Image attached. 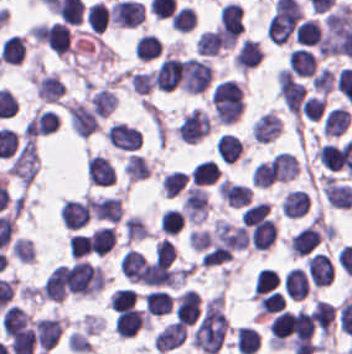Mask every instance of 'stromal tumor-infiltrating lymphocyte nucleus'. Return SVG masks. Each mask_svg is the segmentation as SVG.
<instances>
[{"mask_svg":"<svg viewBox=\"0 0 352 354\" xmlns=\"http://www.w3.org/2000/svg\"><path fill=\"white\" fill-rule=\"evenodd\" d=\"M222 43L218 27L205 30L196 39L195 50L202 55H216Z\"/></svg>","mask_w":352,"mask_h":354,"instance_id":"40","label":"stromal tumor-infiltrating lymphocyte nucleus"},{"mask_svg":"<svg viewBox=\"0 0 352 354\" xmlns=\"http://www.w3.org/2000/svg\"><path fill=\"white\" fill-rule=\"evenodd\" d=\"M186 182L185 171L171 170L160 181L161 192L165 197H172Z\"/></svg>","mask_w":352,"mask_h":354,"instance_id":"49","label":"stromal tumor-infiltrating lymphocyte nucleus"},{"mask_svg":"<svg viewBox=\"0 0 352 354\" xmlns=\"http://www.w3.org/2000/svg\"><path fill=\"white\" fill-rule=\"evenodd\" d=\"M309 206V197L304 190L292 189L281 200L280 212L287 217H300Z\"/></svg>","mask_w":352,"mask_h":354,"instance_id":"29","label":"stromal tumor-infiltrating lymphocyte nucleus"},{"mask_svg":"<svg viewBox=\"0 0 352 354\" xmlns=\"http://www.w3.org/2000/svg\"><path fill=\"white\" fill-rule=\"evenodd\" d=\"M185 217L181 209L168 208L163 212L160 230L166 235H175L182 227Z\"/></svg>","mask_w":352,"mask_h":354,"instance_id":"48","label":"stromal tumor-infiltrating lymphocyte nucleus"},{"mask_svg":"<svg viewBox=\"0 0 352 354\" xmlns=\"http://www.w3.org/2000/svg\"><path fill=\"white\" fill-rule=\"evenodd\" d=\"M260 346V337L249 325H242L235 330L236 350L243 354H251Z\"/></svg>","mask_w":352,"mask_h":354,"instance_id":"36","label":"stromal tumor-infiltrating lymphocyte nucleus"},{"mask_svg":"<svg viewBox=\"0 0 352 354\" xmlns=\"http://www.w3.org/2000/svg\"><path fill=\"white\" fill-rule=\"evenodd\" d=\"M311 86L316 91L328 92L334 85V74L326 68L319 69L310 79Z\"/></svg>","mask_w":352,"mask_h":354,"instance_id":"57","label":"stromal tumor-infiltrating lymphocyte nucleus"},{"mask_svg":"<svg viewBox=\"0 0 352 354\" xmlns=\"http://www.w3.org/2000/svg\"><path fill=\"white\" fill-rule=\"evenodd\" d=\"M220 29L227 37H235L241 31L242 7L233 1H226L218 10Z\"/></svg>","mask_w":352,"mask_h":354,"instance_id":"20","label":"stromal tumor-infiltrating lymphocyte nucleus"},{"mask_svg":"<svg viewBox=\"0 0 352 354\" xmlns=\"http://www.w3.org/2000/svg\"><path fill=\"white\" fill-rule=\"evenodd\" d=\"M128 82L134 93L148 94L151 87V76L145 70H129Z\"/></svg>","mask_w":352,"mask_h":354,"instance_id":"55","label":"stromal tumor-infiltrating lymphocyte nucleus"},{"mask_svg":"<svg viewBox=\"0 0 352 354\" xmlns=\"http://www.w3.org/2000/svg\"><path fill=\"white\" fill-rule=\"evenodd\" d=\"M119 261L125 279L139 281L146 263L140 250L127 248L121 255Z\"/></svg>","mask_w":352,"mask_h":354,"instance_id":"32","label":"stromal tumor-infiltrating lymphocyte nucleus"},{"mask_svg":"<svg viewBox=\"0 0 352 354\" xmlns=\"http://www.w3.org/2000/svg\"><path fill=\"white\" fill-rule=\"evenodd\" d=\"M27 313L14 305L4 308L0 319V328L2 330L26 326L30 322Z\"/></svg>","mask_w":352,"mask_h":354,"instance_id":"47","label":"stromal tumor-infiltrating lymphocyte nucleus"},{"mask_svg":"<svg viewBox=\"0 0 352 354\" xmlns=\"http://www.w3.org/2000/svg\"><path fill=\"white\" fill-rule=\"evenodd\" d=\"M78 264L55 266L41 286V297L61 301L77 280Z\"/></svg>","mask_w":352,"mask_h":354,"instance_id":"4","label":"stromal tumor-infiltrating lymphocyte nucleus"},{"mask_svg":"<svg viewBox=\"0 0 352 354\" xmlns=\"http://www.w3.org/2000/svg\"><path fill=\"white\" fill-rule=\"evenodd\" d=\"M64 89L63 83L53 74L41 75L35 81V95L46 101L59 99Z\"/></svg>","mask_w":352,"mask_h":354,"instance_id":"34","label":"stromal tumor-infiltrating lymphocyte nucleus"},{"mask_svg":"<svg viewBox=\"0 0 352 354\" xmlns=\"http://www.w3.org/2000/svg\"><path fill=\"white\" fill-rule=\"evenodd\" d=\"M277 234L273 218H266L250 229L247 234L248 243L252 248L267 249Z\"/></svg>","mask_w":352,"mask_h":354,"instance_id":"25","label":"stromal tumor-infiltrating lymphocyte nucleus"},{"mask_svg":"<svg viewBox=\"0 0 352 354\" xmlns=\"http://www.w3.org/2000/svg\"><path fill=\"white\" fill-rule=\"evenodd\" d=\"M38 166V153L35 140L25 137L9 165L10 172L24 185H28Z\"/></svg>","mask_w":352,"mask_h":354,"instance_id":"5","label":"stromal tumor-infiltrating lymphocyte nucleus"},{"mask_svg":"<svg viewBox=\"0 0 352 354\" xmlns=\"http://www.w3.org/2000/svg\"><path fill=\"white\" fill-rule=\"evenodd\" d=\"M210 126L206 111L194 106L182 116L175 131L183 141L195 142L210 129Z\"/></svg>","mask_w":352,"mask_h":354,"instance_id":"8","label":"stromal tumor-infiltrating lymphocyte nucleus"},{"mask_svg":"<svg viewBox=\"0 0 352 354\" xmlns=\"http://www.w3.org/2000/svg\"><path fill=\"white\" fill-rule=\"evenodd\" d=\"M170 22L176 31H190L196 22L195 8L186 4L175 8Z\"/></svg>","mask_w":352,"mask_h":354,"instance_id":"44","label":"stromal tumor-infiltrating lymphocyte nucleus"},{"mask_svg":"<svg viewBox=\"0 0 352 354\" xmlns=\"http://www.w3.org/2000/svg\"><path fill=\"white\" fill-rule=\"evenodd\" d=\"M63 226L79 229L89 221V206L84 199L66 198L60 208Z\"/></svg>","mask_w":352,"mask_h":354,"instance_id":"13","label":"stromal tumor-infiltrating lymphocyte nucleus"},{"mask_svg":"<svg viewBox=\"0 0 352 354\" xmlns=\"http://www.w3.org/2000/svg\"><path fill=\"white\" fill-rule=\"evenodd\" d=\"M281 119L272 110H264L253 119L252 136L254 141H267L278 135Z\"/></svg>","mask_w":352,"mask_h":354,"instance_id":"19","label":"stromal tumor-infiltrating lymphocyte nucleus"},{"mask_svg":"<svg viewBox=\"0 0 352 354\" xmlns=\"http://www.w3.org/2000/svg\"><path fill=\"white\" fill-rule=\"evenodd\" d=\"M320 164L329 171H337L340 168V145L323 142L316 147Z\"/></svg>","mask_w":352,"mask_h":354,"instance_id":"46","label":"stromal tumor-infiltrating lymphocyte nucleus"},{"mask_svg":"<svg viewBox=\"0 0 352 354\" xmlns=\"http://www.w3.org/2000/svg\"><path fill=\"white\" fill-rule=\"evenodd\" d=\"M145 307L152 315H162L167 313L172 301L165 290L153 289L143 296Z\"/></svg>","mask_w":352,"mask_h":354,"instance_id":"39","label":"stromal tumor-infiltrating lymphocyte nucleus"},{"mask_svg":"<svg viewBox=\"0 0 352 354\" xmlns=\"http://www.w3.org/2000/svg\"><path fill=\"white\" fill-rule=\"evenodd\" d=\"M160 50L161 43L151 32L139 36L134 46L135 55L147 60L156 57Z\"/></svg>","mask_w":352,"mask_h":354,"instance_id":"43","label":"stromal tumor-infiltrating lymphocyte nucleus"},{"mask_svg":"<svg viewBox=\"0 0 352 354\" xmlns=\"http://www.w3.org/2000/svg\"><path fill=\"white\" fill-rule=\"evenodd\" d=\"M282 288L287 295L295 300L307 294L309 283L299 266H292L283 274Z\"/></svg>","mask_w":352,"mask_h":354,"instance_id":"27","label":"stromal tumor-infiltrating lymphocyte nucleus"},{"mask_svg":"<svg viewBox=\"0 0 352 354\" xmlns=\"http://www.w3.org/2000/svg\"><path fill=\"white\" fill-rule=\"evenodd\" d=\"M279 280L273 269L261 268L254 274L252 284V297H260L272 291Z\"/></svg>","mask_w":352,"mask_h":354,"instance_id":"41","label":"stromal tumor-infiltrating lymphocyte nucleus"},{"mask_svg":"<svg viewBox=\"0 0 352 354\" xmlns=\"http://www.w3.org/2000/svg\"><path fill=\"white\" fill-rule=\"evenodd\" d=\"M85 22L94 31H103L107 26V7L102 1H95L85 10Z\"/></svg>","mask_w":352,"mask_h":354,"instance_id":"45","label":"stromal tumor-infiltrating lymphocyte nucleus"},{"mask_svg":"<svg viewBox=\"0 0 352 354\" xmlns=\"http://www.w3.org/2000/svg\"><path fill=\"white\" fill-rule=\"evenodd\" d=\"M285 302L280 292L270 291L258 297L257 308L259 315L279 312Z\"/></svg>","mask_w":352,"mask_h":354,"instance_id":"52","label":"stromal tumor-infiltrating lymphocyte nucleus"},{"mask_svg":"<svg viewBox=\"0 0 352 354\" xmlns=\"http://www.w3.org/2000/svg\"><path fill=\"white\" fill-rule=\"evenodd\" d=\"M263 56L257 41L252 38H245L235 53L236 64L238 67H252Z\"/></svg>","mask_w":352,"mask_h":354,"instance_id":"35","label":"stromal tumor-infiltrating lymphocyte nucleus"},{"mask_svg":"<svg viewBox=\"0 0 352 354\" xmlns=\"http://www.w3.org/2000/svg\"><path fill=\"white\" fill-rule=\"evenodd\" d=\"M144 327L143 310L129 306L121 309L113 320L114 332L121 337H131Z\"/></svg>","mask_w":352,"mask_h":354,"instance_id":"15","label":"stromal tumor-infiltrating lymphocyte nucleus"},{"mask_svg":"<svg viewBox=\"0 0 352 354\" xmlns=\"http://www.w3.org/2000/svg\"><path fill=\"white\" fill-rule=\"evenodd\" d=\"M298 20L293 16L272 13L267 20L266 33L272 42H285L291 34Z\"/></svg>","mask_w":352,"mask_h":354,"instance_id":"24","label":"stromal tumor-infiltrating lymphocyte nucleus"},{"mask_svg":"<svg viewBox=\"0 0 352 354\" xmlns=\"http://www.w3.org/2000/svg\"><path fill=\"white\" fill-rule=\"evenodd\" d=\"M113 310H121L135 303V291L130 287H117L108 297Z\"/></svg>","mask_w":352,"mask_h":354,"instance_id":"54","label":"stromal tumor-infiltrating lymphocyte nucleus"},{"mask_svg":"<svg viewBox=\"0 0 352 354\" xmlns=\"http://www.w3.org/2000/svg\"><path fill=\"white\" fill-rule=\"evenodd\" d=\"M320 32L319 22L314 18L308 17L299 22L294 32V40L304 45H315Z\"/></svg>","mask_w":352,"mask_h":354,"instance_id":"42","label":"stromal tumor-infiltrating lymphocyte nucleus"},{"mask_svg":"<svg viewBox=\"0 0 352 354\" xmlns=\"http://www.w3.org/2000/svg\"><path fill=\"white\" fill-rule=\"evenodd\" d=\"M212 68L207 59L196 56L184 58L180 83L187 93L206 89L211 80Z\"/></svg>","mask_w":352,"mask_h":354,"instance_id":"6","label":"stromal tumor-infiltrating lymphocyte nucleus"},{"mask_svg":"<svg viewBox=\"0 0 352 354\" xmlns=\"http://www.w3.org/2000/svg\"><path fill=\"white\" fill-rule=\"evenodd\" d=\"M251 190L246 183L220 180L216 192L227 205L238 208L248 204Z\"/></svg>","mask_w":352,"mask_h":354,"instance_id":"18","label":"stromal tumor-infiltrating lymphocyte nucleus"},{"mask_svg":"<svg viewBox=\"0 0 352 354\" xmlns=\"http://www.w3.org/2000/svg\"><path fill=\"white\" fill-rule=\"evenodd\" d=\"M307 267L314 286H325L330 283L334 266L327 254L316 252L308 258Z\"/></svg>","mask_w":352,"mask_h":354,"instance_id":"23","label":"stromal tumor-infiltrating lymphocyte nucleus"},{"mask_svg":"<svg viewBox=\"0 0 352 354\" xmlns=\"http://www.w3.org/2000/svg\"><path fill=\"white\" fill-rule=\"evenodd\" d=\"M298 169L296 156L288 150H280L254 166L252 183L256 186H270L294 177Z\"/></svg>","mask_w":352,"mask_h":354,"instance_id":"1","label":"stromal tumor-infiltrating lymphocyte nucleus"},{"mask_svg":"<svg viewBox=\"0 0 352 354\" xmlns=\"http://www.w3.org/2000/svg\"><path fill=\"white\" fill-rule=\"evenodd\" d=\"M88 183L108 186L114 183L115 170L108 157L91 154L85 162Z\"/></svg>","mask_w":352,"mask_h":354,"instance_id":"11","label":"stromal tumor-infiltrating lymphocyte nucleus"},{"mask_svg":"<svg viewBox=\"0 0 352 354\" xmlns=\"http://www.w3.org/2000/svg\"><path fill=\"white\" fill-rule=\"evenodd\" d=\"M60 334V317H40L34 322L35 342L44 353L58 341Z\"/></svg>","mask_w":352,"mask_h":354,"instance_id":"14","label":"stromal tumor-infiltrating lymphocyte nucleus"},{"mask_svg":"<svg viewBox=\"0 0 352 354\" xmlns=\"http://www.w3.org/2000/svg\"><path fill=\"white\" fill-rule=\"evenodd\" d=\"M288 333L286 311H279L268 324V334L271 342H283Z\"/></svg>","mask_w":352,"mask_h":354,"instance_id":"53","label":"stromal tumor-infiltrating lymphocyte nucleus"},{"mask_svg":"<svg viewBox=\"0 0 352 354\" xmlns=\"http://www.w3.org/2000/svg\"><path fill=\"white\" fill-rule=\"evenodd\" d=\"M24 51V39L17 33H10L3 41L0 51L1 62L19 63Z\"/></svg>","mask_w":352,"mask_h":354,"instance_id":"38","label":"stromal tumor-infiltrating lymphocyte nucleus"},{"mask_svg":"<svg viewBox=\"0 0 352 354\" xmlns=\"http://www.w3.org/2000/svg\"><path fill=\"white\" fill-rule=\"evenodd\" d=\"M219 166L217 162L210 159H202L192 165L189 179L192 183H212L217 177Z\"/></svg>","mask_w":352,"mask_h":354,"instance_id":"37","label":"stromal tumor-infiltrating lymphocyte nucleus"},{"mask_svg":"<svg viewBox=\"0 0 352 354\" xmlns=\"http://www.w3.org/2000/svg\"><path fill=\"white\" fill-rule=\"evenodd\" d=\"M269 206L264 201L248 204L240 216L241 224L251 227L266 217Z\"/></svg>","mask_w":352,"mask_h":354,"instance_id":"51","label":"stromal tumor-infiltrating lymphocyte nucleus"},{"mask_svg":"<svg viewBox=\"0 0 352 354\" xmlns=\"http://www.w3.org/2000/svg\"><path fill=\"white\" fill-rule=\"evenodd\" d=\"M215 149L222 160L232 162L241 156L243 142L234 132H221L216 141Z\"/></svg>","mask_w":352,"mask_h":354,"instance_id":"26","label":"stromal tumor-infiltrating lymphocyte nucleus"},{"mask_svg":"<svg viewBox=\"0 0 352 354\" xmlns=\"http://www.w3.org/2000/svg\"><path fill=\"white\" fill-rule=\"evenodd\" d=\"M70 255L74 258H79L85 255L89 249V235L73 234L68 245Z\"/></svg>","mask_w":352,"mask_h":354,"instance_id":"59","label":"stromal tumor-infiltrating lymphocyte nucleus"},{"mask_svg":"<svg viewBox=\"0 0 352 354\" xmlns=\"http://www.w3.org/2000/svg\"><path fill=\"white\" fill-rule=\"evenodd\" d=\"M350 121V114L342 105H335L323 118L321 132L326 135H340Z\"/></svg>","mask_w":352,"mask_h":354,"instance_id":"31","label":"stromal tumor-infiltrating lymphocyte nucleus"},{"mask_svg":"<svg viewBox=\"0 0 352 354\" xmlns=\"http://www.w3.org/2000/svg\"><path fill=\"white\" fill-rule=\"evenodd\" d=\"M88 203L93 219L117 223L122 211L118 196H90Z\"/></svg>","mask_w":352,"mask_h":354,"instance_id":"17","label":"stromal tumor-infiltrating lymphocyte nucleus"},{"mask_svg":"<svg viewBox=\"0 0 352 354\" xmlns=\"http://www.w3.org/2000/svg\"><path fill=\"white\" fill-rule=\"evenodd\" d=\"M90 253L107 254L115 244L113 225H99L93 229L89 239Z\"/></svg>","mask_w":352,"mask_h":354,"instance_id":"30","label":"stromal tumor-infiltrating lymphocyte nucleus"},{"mask_svg":"<svg viewBox=\"0 0 352 354\" xmlns=\"http://www.w3.org/2000/svg\"><path fill=\"white\" fill-rule=\"evenodd\" d=\"M104 286V273L99 266L86 259L72 264V292L75 295L94 296Z\"/></svg>","mask_w":352,"mask_h":354,"instance_id":"3","label":"stromal tumor-infiltrating lymphocyte nucleus"},{"mask_svg":"<svg viewBox=\"0 0 352 354\" xmlns=\"http://www.w3.org/2000/svg\"><path fill=\"white\" fill-rule=\"evenodd\" d=\"M289 68L298 75H311L316 61L311 51L304 47L293 49L288 55Z\"/></svg>","mask_w":352,"mask_h":354,"instance_id":"33","label":"stromal tumor-infiltrating lymphocyte nucleus"},{"mask_svg":"<svg viewBox=\"0 0 352 354\" xmlns=\"http://www.w3.org/2000/svg\"><path fill=\"white\" fill-rule=\"evenodd\" d=\"M185 326L176 322H169L156 332L154 345L155 349L167 351L181 344L184 338Z\"/></svg>","mask_w":352,"mask_h":354,"instance_id":"28","label":"stromal tumor-infiltrating lymphocyte nucleus"},{"mask_svg":"<svg viewBox=\"0 0 352 354\" xmlns=\"http://www.w3.org/2000/svg\"><path fill=\"white\" fill-rule=\"evenodd\" d=\"M320 241L317 229L310 223L303 225L288 239L289 250L297 255L304 256Z\"/></svg>","mask_w":352,"mask_h":354,"instance_id":"21","label":"stromal tumor-infiltrating lymphocyte nucleus"},{"mask_svg":"<svg viewBox=\"0 0 352 354\" xmlns=\"http://www.w3.org/2000/svg\"><path fill=\"white\" fill-rule=\"evenodd\" d=\"M68 120L78 136H87L98 125L97 115L93 108L83 101H70L67 106Z\"/></svg>","mask_w":352,"mask_h":354,"instance_id":"9","label":"stromal tumor-infiltrating lymphocyte nucleus"},{"mask_svg":"<svg viewBox=\"0 0 352 354\" xmlns=\"http://www.w3.org/2000/svg\"><path fill=\"white\" fill-rule=\"evenodd\" d=\"M321 193L328 204L335 207H348L352 202V187L347 182L323 180Z\"/></svg>","mask_w":352,"mask_h":354,"instance_id":"22","label":"stromal tumor-infiltrating lymphocyte nucleus"},{"mask_svg":"<svg viewBox=\"0 0 352 354\" xmlns=\"http://www.w3.org/2000/svg\"><path fill=\"white\" fill-rule=\"evenodd\" d=\"M106 140L114 147L135 150L140 145V134L128 124L114 121L106 130Z\"/></svg>","mask_w":352,"mask_h":354,"instance_id":"12","label":"stromal tumor-infiltrating lymphocyte nucleus"},{"mask_svg":"<svg viewBox=\"0 0 352 354\" xmlns=\"http://www.w3.org/2000/svg\"><path fill=\"white\" fill-rule=\"evenodd\" d=\"M123 169L130 179L143 178L149 174V167L144 156L131 152L124 162Z\"/></svg>","mask_w":352,"mask_h":354,"instance_id":"50","label":"stromal tumor-infiltrating lymphocyte nucleus"},{"mask_svg":"<svg viewBox=\"0 0 352 354\" xmlns=\"http://www.w3.org/2000/svg\"><path fill=\"white\" fill-rule=\"evenodd\" d=\"M200 312V299L197 291L184 290L174 300V313L177 321L185 325L197 319Z\"/></svg>","mask_w":352,"mask_h":354,"instance_id":"16","label":"stromal tumor-infiltrating lymphocyte nucleus"},{"mask_svg":"<svg viewBox=\"0 0 352 354\" xmlns=\"http://www.w3.org/2000/svg\"><path fill=\"white\" fill-rule=\"evenodd\" d=\"M37 39L62 57L71 48L66 22L56 20L42 23L38 27Z\"/></svg>","mask_w":352,"mask_h":354,"instance_id":"7","label":"stromal tumor-infiltrating lymphocyte nucleus"},{"mask_svg":"<svg viewBox=\"0 0 352 354\" xmlns=\"http://www.w3.org/2000/svg\"><path fill=\"white\" fill-rule=\"evenodd\" d=\"M10 251L19 261H32L33 246L31 239L18 237L12 243Z\"/></svg>","mask_w":352,"mask_h":354,"instance_id":"58","label":"stromal tumor-infiltrating lymphocyte nucleus"},{"mask_svg":"<svg viewBox=\"0 0 352 354\" xmlns=\"http://www.w3.org/2000/svg\"><path fill=\"white\" fill-rule=\"evenodd\" d=\"M211 102L218 122L231 124L243 110V93L238 83L225 79L212 89Z\"/></svg>","mask_w":352,"mask_h":354,"instance_id":"2","label":"stromal tumor-infiltrating lymphocyte nucleus"},{"mask_svg":"<svg viewBox=\"0 0 352 354\" xmlns=\"http://www.w3.org/2000/svg\"><path fill=\"white\" fill-rule=\"evenodd\" d=\"M324 107V99L320 95H307L300 109L309 120H316Z\"/></svg>","mask_w":352,"mask_h":354,"instance_id":"56","label":"stromal tumor-infiltrating lymphocyte nucleus"},{"mask_svg":"<svg viewBox=\"0 0 352 354\" xmlns=\"http://www.w3.org/2000/svg\"><path fill=\"white\" fill-rule=\"evenodd\" d=\"M183 68L181 59L165 57L153 70L152 85L156 90H172L180 81Z\"/></svg>","mask_w":352,"mask_h":354,"instance_id":"10","label":"stromal tumor-infiltrating lymphocyte nucleus"}]
</instances>
